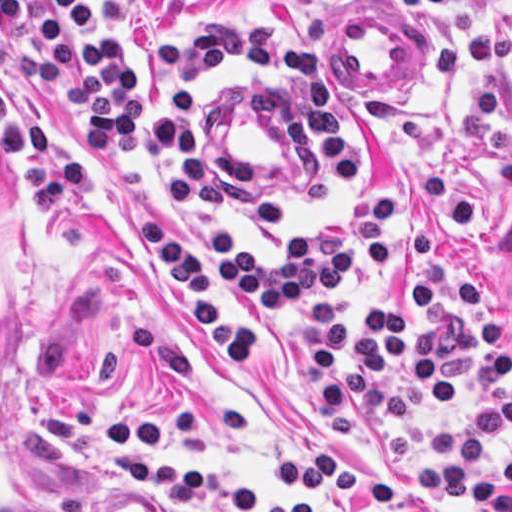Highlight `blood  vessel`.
<instances>
[{"instance_id":"obj_1","label":"blood vessel","mask_w":512,"mask_h":512,"mask_svg":"<svg viewBox=\"0 0 512 512\" xmlns=\"http://www.w3.org/2000/svg\"><path fill=\"white\" fill-rule=\"evenodd\" d=\"M375 15L342 17L339 65L357 88H404L418 68V30Z\"/></svg>"}]
</instances>
